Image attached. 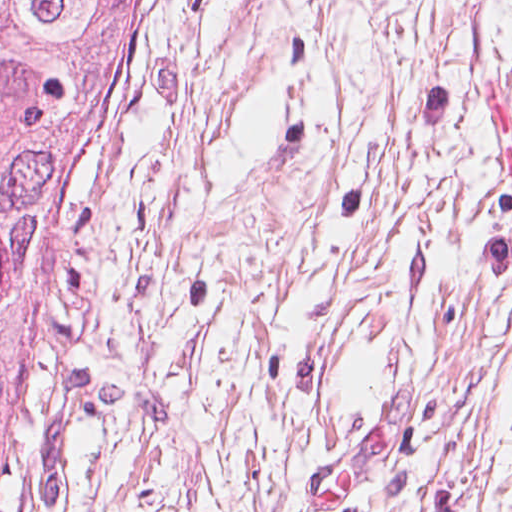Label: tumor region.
<instances>
[{"label":"tumor region","instance_id":"obj_1","mask_svg":"<svg viewBox=\"0 0 512 512\" xmlns=\"http://www.w3.org/2000/svg\"><path fill=\"white\" fill-rule=\"evenodd\" d=\"M145 0H0V446L77 156L114 132Z\"/></svg>","mask_w":512,"mask_h":512}]
</instances>
